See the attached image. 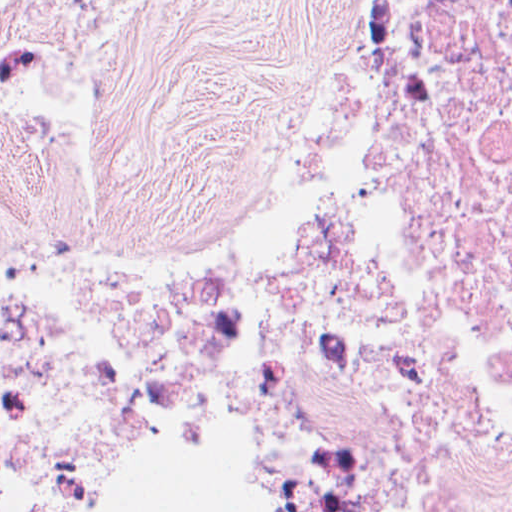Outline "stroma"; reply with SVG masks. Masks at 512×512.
Listing matches in <instances>:
<instances>
[{
  "label": "stroma",
  "instance_id": "stroma-1",
  "mask_svg": "<svg viewBox=\"0 0 512 512\" xmlns=\"http://www.w3.org/2000/svg\"><path fill=\"white\" fill-rule=\"evenodd\" d=\"M73 124L69 229L40 268L182 284L247 260L316 111L349 90V0H124ZM98 396L103 512H255L215 431H175L156 386L68 362L0 476L71 446Z\"/></svg>",
  "mask_w": 512,
  "mask_h": 512
}]
</instances>
